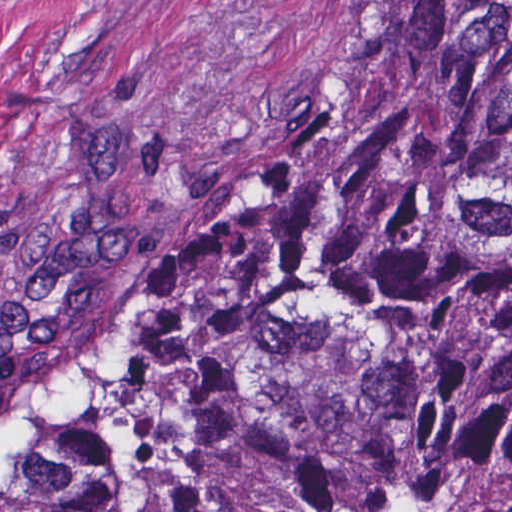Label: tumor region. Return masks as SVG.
<instances>
[{
	"instance_id": "e687c5a6",
	"label": "tumor region",
	"mask_w": 512,
	"mask_h": 512,
	"mask_svg": "<svg viewBox=\"0 0 512 512\" xmlns=\"http://www.w3.org/2000/svg\"><path fill=\"white\" fill-rule=\"evenodd\" d=\"M0 503L512 512V0H385Z\"/></svg>"
}]
</instances>
